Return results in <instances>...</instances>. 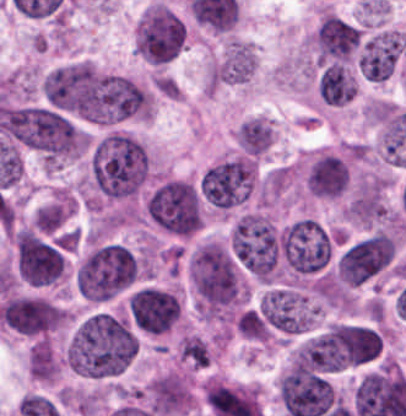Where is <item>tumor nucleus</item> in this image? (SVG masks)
<instances>
[{
    "instance_id": "tumor-nucleus-5",
    "label": "tumor nucleus",
    "mask_w": 406,
    "mask_h": 416,
    "mask_svg": "<svg viewBox=\"0 0 406 416\" xmlns=\"http://www.w3.org/2000/svg\"><path fill=\"white\" fill-rule=\"evenodd\" d=\"M150 221L171 234L188 235L201 224L196 187L185 178L163 177L149 190L145 203Z\"/></svg>"
},
{
    "instance_id": "tumor-nucleus-2",
    "label": "tumor nucleus",
    "mask_w": 406,
    "mask_h": 416,
    "mask_svg": "<svg viewBox=\"0 0 406 416\" xmlns=\"http://www.w3.org/2000/svg\"><path fill=\"white\" fill-rule=\"evenodd\" d=\"M91 183L109 198H127L139 191L148 177V154L129 130L109 129L90 150Z\"/></svg>"
},
{
    "instance_id": "tumor-nucleus-3",
    "label": "tumor nucleus",
    "mask_w": 406,
    "mask_h": 416,
    "mask_svg": "<svg viewBox=\"0 0 406 416\" xmlns=\"http://www.w3.org/2000/svg\"><path fill=\"white\" fill-rule=\"evenodd\" d=\"M230 250L254 279L272 280L281 270V235L260 211H247L238 217L230 232Z\"/></svg>"
},
{
    "instance_id": "tumor-nucleus-9",
    "label": "tumor nucleus",
    "mask_w": 406,
    "mask_h": 416,
    "mask_svg": "<svg viewBox=\"0 0 406 416\" xmlns=\"http://www.w3.org/2000/svg\"><path fill=\"white\" fill-rule=\"evenodd\" d=\"M394 254L390 235L376 232L347 247L338 264V276L345 285H358L388 265Z\"/></svg>"
},
{
    "instance_id": "tumor-nucleus-7",
    "label": "tumor nucleus",
    "mask_w": 406,
    "mask_h": 416,
    "mask_svg": "<svg viewBox=\"0 0 406 416\" xmlns=\"http://www.w3.org/2000/svg\"><path fill=\"white\" fill-rule=\"evenodd\" d=\"M255 176V161L238 152L205 168L199 192L211 207L226 211L243 203L252 191Z\"/></svg>"
},
{
    "instance_id": "tumor-nucleus-1",
    "label": "tumor nucleus",
    "mask_w": 406,
    "mask_h": 416,
    "mask_svg": "<svg viewBox=\"0 0 406 416\" xmlns=\"http://www.w3.org/2000/svg\"><path fill=\"white\" fill-rule=\"evenodd\" d=\"M137 342L118 317L97 311L82 320L66 350L67 365L88 376L120 372L132 359Z\"/></svg>"
},
{
    "instance_id": "tumor-nucleus-10",
    "label": "tumor nucleus",
    "mask_w": 406,
    "mask_h": 416,
    "mask_svg": "<svg viewBox=\"0 0 406 416\" xmlns=\"http://www.w3.org/2000/svg\"><path fill=\"white\" fill-rule=\"evenodd\" d=\"M259 309L273 326L292 333L311 326L319 311L304 292L283 287L266 290L260 297Z\"/></svg>"
},
{
    "instance_id": "tumor-nucleus-6",
    "label": "tumor nucleus",
    "mask_w": 406,
    "mask_h": 416,
    "mask_svg": "<svg viewBox=\"0 0 406 416\" xmlns=\"http://www.w3.org/2000/svg\"><path fill=\"white\" fill-rule=\"evenodd\" d=\"M279 236L282 266L287 277L302 278L317 272L329 261L330 232L310 216L284 225Z\"/></svg>"
},
{
    "instance_id": "tumor-nucleus-12",
    "label": "tumor nucleus",
    "mask_w": 406,
    "mask_h": 416,
    "mask_svg": "<svg viewBox=\"0 0 406 416\" xmlns=\"http://www.w3.org/2000/svg\"><path fill=\"white\" fill-rule=\"evenodd\" d=\"M303 188L320 198H336L348 185V167L344 155L319 149L305 164Z\"/></svg>"
},
{
    "instance_id": "tumor-nucleus-14",
    "label": "tumor nucleus",
    "mask_w": 406,
    "mask_h": 416,
    "mask_svg": "<svg viewBox=\"0 0 406 416\" xmlns=\"http://www.w3.org/2000/svg\"><path fill=\"white\" fill-rule=\"evenodd\" d=\"M256 67L254 50L249 43H230L217 69V80L238 85L247 82Z\"/></svg>"
},
{
    "instance_id": "tumor-nucleus-4",
    "label": "tumor nucleus",
    "mask_w": 406,
    "mask_h": 416,
    "mask_svg": "<svg viewBox=\"0 0 406 416\" xmlns=\"http://www.w3.org/2000/svg\"><path fill=\"white\" fill-rule=\"evenodd\" d=\"M138 263L124 244L109 243L94 250L77 267L75 286L92 301H107L135 280Z\"/></svg>"
},
{
    "instance_id": "tumor-nucleus-11",
    "label": "tumor nucleus",
    "mask_w": 406,
    "mask_h": 416,
    "mask_svg": "<svg viewBox=\"0 0 406 416\" xmlns=\"http://www.w3.org/2000/svg\"><path fill=\"white\" fill-rule=\"evenodd\" d=\"M126 307L137 326L153 333L169 328L179 315L177 295L158 287H139L126 299Z\"/></svg>"
},
{
    "instance_id": "tumor-nucleus-16",
    "label": "tumor nucleus",
    "mask_w": 406,
    "mask_h": 416,
    "mask_svg": "<svg viewBox=\"0 0 406 416\" xmlns=\"http://www.w3.org/2000/svg\"><path fill=\"white\" fill-rule=\"evenodd\" d=\"M274 128L267 118L253 116L243 120L234 132L236 146L249 156H259L270 147Z\"/></svg>"
},
{
    "instance_id": "tumor-nucleus-8",
    "label": "tumor nucleus",
    "mask_w": 406,
    "mask_h": 416,
    "mask_svg": "<svg viewBox=\"0 0 406 416\" xmlns=\"http://www.w3.org/2000/svg\"><path fill=\"white\" fill-rule=\"evenodd\" d=\"M18 276L33 286H44L61 277L65 262L58 249L30 229L13 232Z\"/></svg>"
},
{
    "instance_id": "tumor-nucleus-13",
    "label": "tumor nucleus",
    "mask_w": 406,
    "mask_h": 416,
    "mask_svg": "<svg viewBox=\"0 0 406 416\" xmlns=\"http://www.w3.org/2000/svg\"><path fill=\"white\" fill-rule=\"evenodd\" d=\"M388 209L382 189L357 188L345 205V220L374 226L386 215Z\"/></svg>"
},
{
    "instance_id": "tumor-nucleus-15",
    "label": "tumor nucleus",
    "mask_w": 406,
    "mask_h": 416,
    "mask_svg": "<svg viewBox=\"0 0 406 416\" xmlns=\"http://www.w3.org/2000/svg\"><path fill=\"white\" fill-rule=\"evenodd\" d=\"M317 90L324 103L344 104L355 96L357 86L344 65L333 63L321 72Z\"/></svg>"
}]
</instances>
